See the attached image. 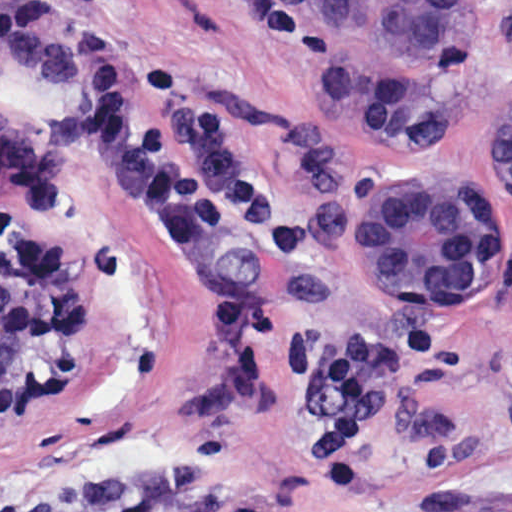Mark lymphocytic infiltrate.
Segmentation results:
<instances>
[{"mask_svg":"<svg viewBox=\"0 0 512 512\" xmlns=\"http://www.w3.org/2000/svg\"><path fill=\"white\" fill-rule=\"evenodd\" d=\"M148 0H17L0 12V59L40 96L73 111V136L123 207L179 241L236 228L291 234L286 193L247 162L227 109L185 80L167 55L139 69L117 24L123 6ZM222 387L249 383L261 343L289 377L317 390L310 455L328 485L365 487L363 454L401 380L434 359L442 333L411 319L375 332L297 335L271 321L240 288L213 289L193 321Z\"/></svg>","mask_w":512,"mask_h":512,"instance_id":"f902f5d3","label":"lymphocytic infiltrate"}]
</instances>
